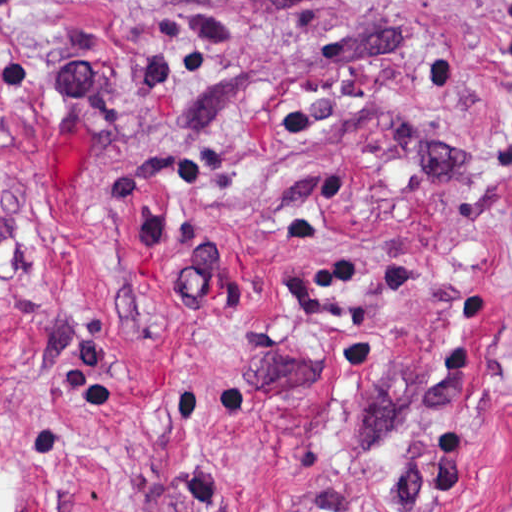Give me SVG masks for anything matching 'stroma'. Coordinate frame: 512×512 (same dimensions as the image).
Listing matches in <instances>:
<instances>
[{
    "label": "stroma",
    "mask_w": 512,
    "mask_h": 512,
    "mask_svg": "<svg viewBox=\"0 0 512 512\" xmlns=\"http://www.w3.org/2000/svg\"><path fill=\"white\" fill-rule=\"evenodd\" d=\"M19 512H512V0H0Z\"/></svg>",
    "instance_id": "35a3bbf8"
}]
</instances>
